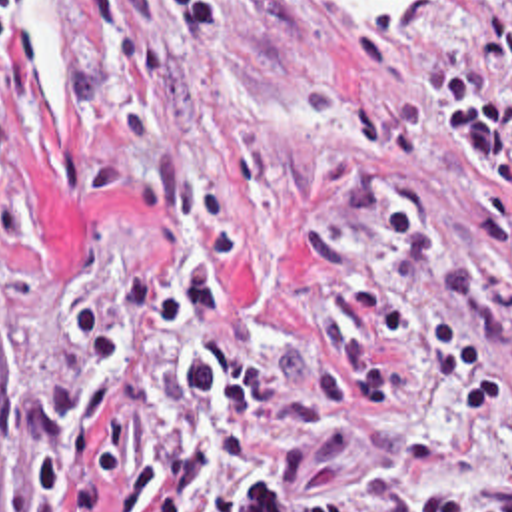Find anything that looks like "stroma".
<instances>
[{"mask_svg":"<svg viewBox=\"0 0 512 512\" xmlns=\"http://www.w3.org/2000/svg\"><path fill=\"white\" fill-rule=\"evenodd\" d=\"M0 47V512H67L95 456L77 460L61 504L33 500L31 434L9 386H57L75 366L63 318L97 306L115 324L121 286L157 272L173 294L199 232L153 218L139 181L163 151L235 228L225 294L249 326L295 338L324 290L303 236L328 212L364 272L402 312L460 328L494 374L476 414L450 376L392 354L398 382L346 418L348 450L299 462L295 428L257 422L251 442L279 500H346L350 512H512V226L506 256L474 238L486 177L438 129L430 71L460 65L512 107V83L476 57L486 15L458 0H408L372 27L346 0H223L231 43L185 59L179 0H13ZM271 362L223 324L191 322L107 406L131 440L107 486L177 446L175 366ZM211 480V450L187 512ZM103 512H111L107 500Z\"/></svg>","mask_w":512,"mask_h":512,"instance_id":"35a3bbf8","label":"stroma"}]
</instances>
